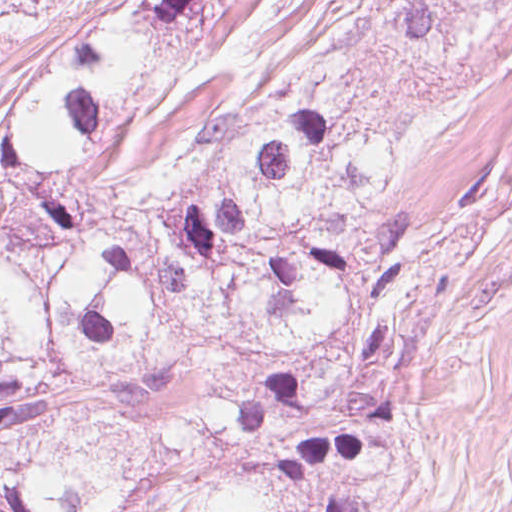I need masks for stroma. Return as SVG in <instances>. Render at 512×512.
<instances>
[{"mask_svg":"<svg viewBox=\"0 0 512 512\" xmlns=\"http://www.w3.org/2000/svg\"><path fill=\"white\" fill-rule=\"evenodd\" d=\"M489 512H512V441Z\"/></svg>","mask_w":512,"mask_h":512,"instance_id":"35a3bbf8","label":"stroma"}]
</instances>
